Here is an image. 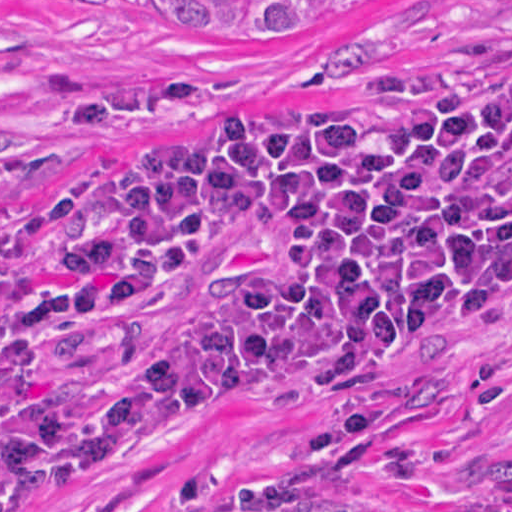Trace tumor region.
I'll use <instances>...</instances> for the list:
<instances>
[{
	"label": "tumor region",
	"instance_id": "e687c5a6",
	"mask_svg": "<svg viewBox=\"0 0 512 512\" xmlns=\"http://www.w3.org/2000/svg\"><path fill=\"white\" fill-rule=\"evenodd\" d=\"M182 35L260 38L274 32L361 16L417 0H162ZM417 512H468L446 499H428ZM488 512H512L501 496Z\"/></svg>",
	"mask_w": 512,
	"mask_h": 512
}]
</instances>
